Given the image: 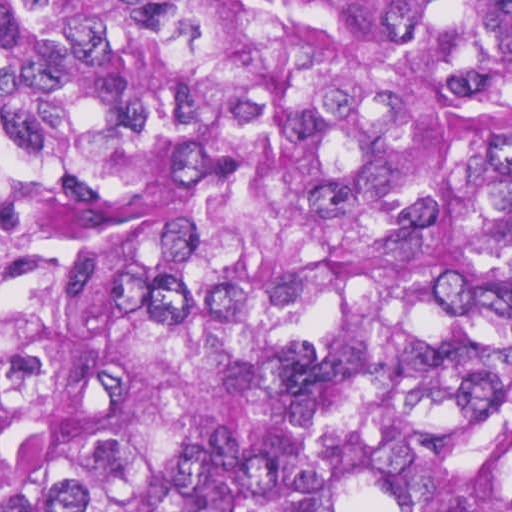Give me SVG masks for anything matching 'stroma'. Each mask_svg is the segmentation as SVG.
<instances>
[{"instance_id":"obj_1","label":"stroma","mask_w":512,"mask_h":512,"mask_svg":"<svg viewBox=\"0 0 512 512\" xmlns=\"http://www.w3.org/2000/svg\"><path fill=\"white\" fill-rule=\"evenodd\" d=\"M47 374L32 359L0 295V414Z\"/></svg>"}]
</instances>
